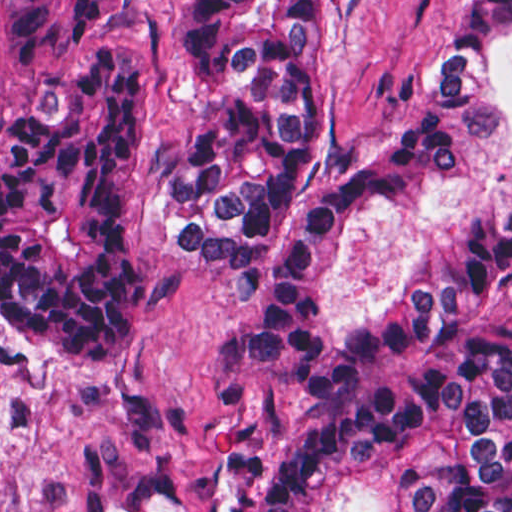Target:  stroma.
<instances>
[{"label": "stroma", "mask_w": 512, "mask_h": 512, "mask_svg": "<svg viewBox=\"0 0 512 512\" xmlns=\"http://www.w3.org/2000/svg\"><path fill=\"white\" fill-rule=\"evenodd\" d=\"M449 0H323V123L328 137L380 139L421 92ZM185 0H141L102 25L142 59L139 246L158 287L155 327L112 373H50L13 344L1 318L0 0V512H103L142 479L200 494L223 432L261 444L257 510L271 461L318 406L341 342L411 291L460 209L512 184V39L480 59L478 93L491 127L446 180L431 209L363 200L312 319L310 381L270 386L246 347L243 294L157 213L159 167L204 107L184 84Z\"/></svg>", "instance_id": "35a3bbf8"}]
</instances>
